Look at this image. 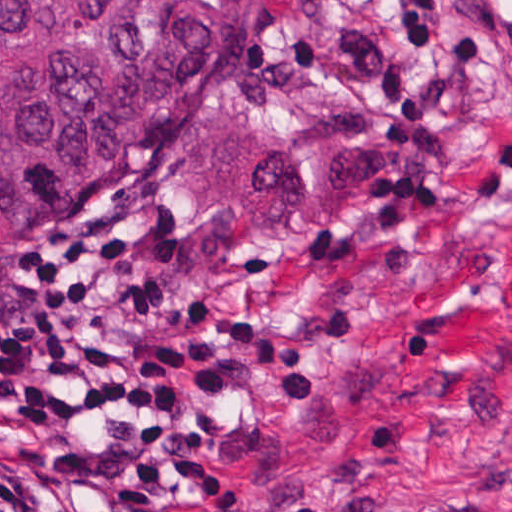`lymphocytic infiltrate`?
Here are the masks:
<instances>
[{"label": "lymphocytic infiltrate", "mask_w": 512, "mask_h": 512, "mask_svg": "<svg viewBox=\"0 0 512 512\" xmlns=\"http://www.w3.org/2000/svg\"><path fill=\"white\" fill-rule=\"evenodd\" d=\"M404 20L382 76L388 140L414 151L459 62L490 49L486 23L453 25L445 0H369ZM512 79V25L502 35ZM512 188V114L475 192ZM198 293L170 215L147 201L133 250L114 230H64L0 271V512H159L165 487L199 512L250 502L232 470L237 380L320 395L311 345Z\"/></svg>", "instance_id": "lymphocytic-infiltrate-1"}]
</instances>
